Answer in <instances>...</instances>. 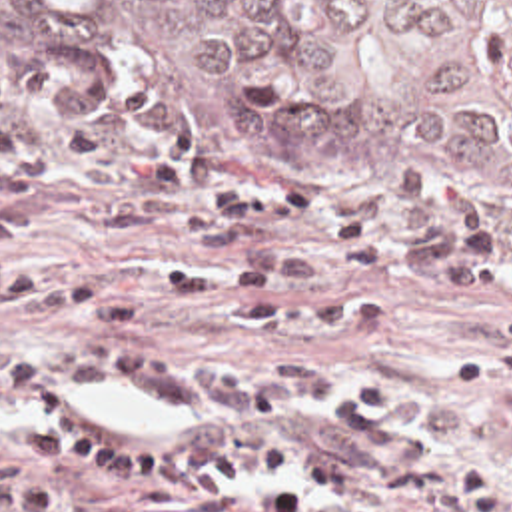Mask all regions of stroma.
Returning <instances> with one entry per match:
<instances>
[{"label":"stroma","mask_w":512,"mask_h":512,"mask_svg":"<svg viewBox=\"0 0 512 512\" xmlns=\"http://www.w3.org/2000/svg\"><path fill=\"white\" fill-rule=\"evenodd\" d=\"M0 87L16 91L42 113L66 121L98 125L152 142L174 158L216 166L241 194H275L289 188H317L343 214H363L397 240L399 264L359 270L335 262L301 232H271L269 240L309 250L331 262L333 274L317 284H273L267 302H319L327 298H375L383 320L367 328H303L275 338L279 360H321L335 384L375 372L397 384L405 400V422L427 442V462L439 472L437 494L419 506L387 502L393 512H512V380H449L447 366L487 344L491 320L471 302L463 286L421 282L407 270L409 230L371 214L363 182L397 172L425 170L439 180H457L481 194L493 218L499 246L512 240V184L483 174L443 166H411L391 158H363L341 166H295L235 158L178 141L142 127L94 93L70 83L52 67L20 55H0ZM12 198L58 226L88 222L98 196L82 188H36L0 196ZM214 250L180 240H114L80 244L74 240L24 238L20 260L34 268L78 276L110 288L136 312L132 324H76L34 320L0 312V346L38 336L46 342L100 354H154L182 364L237 366L257 360L253 338L231 330V284L222 280V300L194 312L174 302L164 278L178 266ZM32 424H0V460L18 458ZM243 490L231 512H251Z\"/></svg>","instance_id":"stroma-1"}]
</instances>
